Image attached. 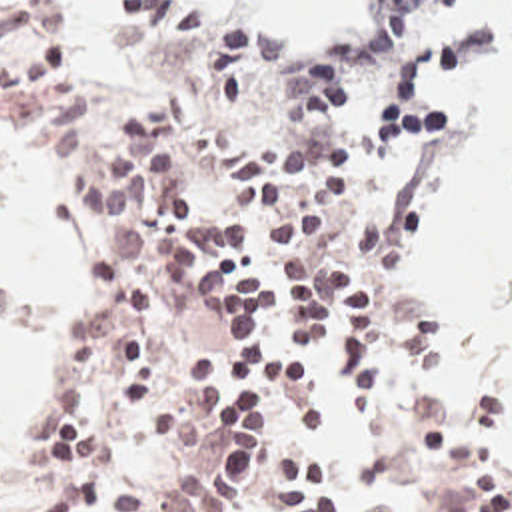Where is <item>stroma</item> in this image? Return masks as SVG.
I'll return each instance as SVG.
<instances>
[{
  "instance_id": "35a3bbf8",
  "label": "stroma",
  "mask_w": 512,
  "mask_h": 512,
  "mask_svg": "<svg viewBox=\"0 0 512 512\" xmlns=\"http://www.w3.org/2000/svg\"><path fill=\"white\" fill-rule=\"evenodd\" d=\"M66 24V16L52 0ZM450 6V4H448ZM446 6V8H448ZM440 10L410 35H384L380 29H336L328 33L322 55H298L314 71H332L340 63L360 67L368 83V129L360 149L342 177L312 209L310 217L370 215L386 231V319L382 365L412 379L436 403L444 405L460 459L472 467L512 507V479L478 457L474 437L500 409L492 393L470 385H440L422 371V313L406 299L398 279V225L402 195L426 163L448 151V131L428 123L414 107L436 75L460 67H490L512 59V16H506L458 45L412 53L416 41L446 12ZM252 24V20H250ZM68 26V24H66ZM260 33L262 29L254 28ZM272 35V33H270ZM110 97H150L110 95ZM0 131L24 159L60 191V173L5 113L0 101ZM78 223V267L60 307V357L56 375L15 437L0 443V497L34 501L44 485L21 467V437L32 415L44 413L62 399V345L68 321L86 303L106 259V221L70 203ZM318 381L328 401V431L310 447L336 477L338 499L364 512H456V489L426 475L408 455L384 415L352 407L332 353L318 359ZM250 512H286L272 485H264Z\"/></svg>"
}]
</instances>
